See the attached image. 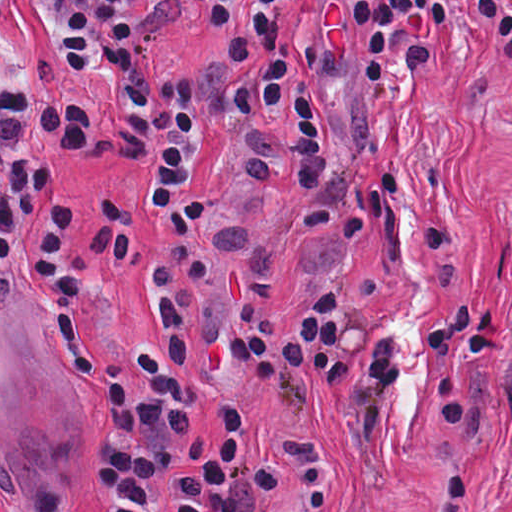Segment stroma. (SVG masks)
<instances>
[{"mask_svg":"<svg viewBox=\"0 0 512 512\" xmlns=\"http://www.w3.org/2000/svg\"><path fill=\"white\" fill-rule=\"evenodd\" d=\"M137 23L154 76L188 73L227 53L228 25L189 0H139ZM0 69L31 93L91 108L93 145L55 148L33 164L49 201L0 265V512L30 498L50 512H101L91 458L109 428V407L70 359L45 264L57 213L106 191L129 244L117 269L85 294L92 333L133 351L157 332L150 255L160 214L132 165L111 151L125 103L106 71L79 72L45 0H10L0 21ZM322 142L331 180L350 190L394 175L392 213L354 234L297 219V192L267 198L244 168L245 143L220 128L200 140L189 195L209 199V277L195 295L191 366L198 399L191 426L207 444L233 410L258 421L267 442L321 447L349 461L343 504L326 512H432L452 465L473 475L459 512H512V50L455 14L440 29V58L386 93H322ZM447 219L450 254L426 268L425 230ZM342 292L358 316L398 333L405 379L392 394L384 447L358 439L352 382L308 405L283 384L265 387L220 331L251 310L292 320L324 288ZM497 296L502 342L480 349L465 387L472 411L452 423L429 386L417 320L449 294ZM288 491L258 512H302Z\"/></svg>","mask_w":512,"mask_h":512,"instance_id":"35a3bbf8","label":"stroma"}]
</instances>
